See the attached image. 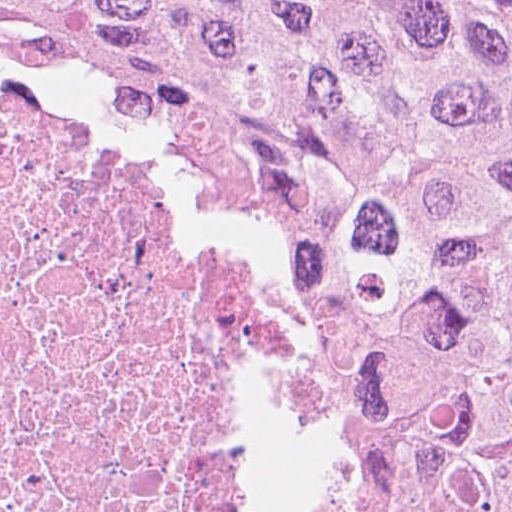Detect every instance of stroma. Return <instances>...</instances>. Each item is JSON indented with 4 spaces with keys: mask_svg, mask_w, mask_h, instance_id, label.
Here are the masks:
<instances>
[{
    "mask_svg": "<svg viewBox=\"0 0 512 512\" xmlns=\"http://www.w3.org/2000/svg\"><path fill=\"white\" fill-rule=\"evenodd\" d=\"M0 89L78 128L86 149L219 245L274 359V417L256 512H407L387 461L344 399L316 320L249 210L245 187L130 104L2 41Z\"/></svg>",
    "mask_w": 512,
    "mask_h": 512,
    "instance_id": "stroma-1",
    "label": "stroma"
}]
</instances>
